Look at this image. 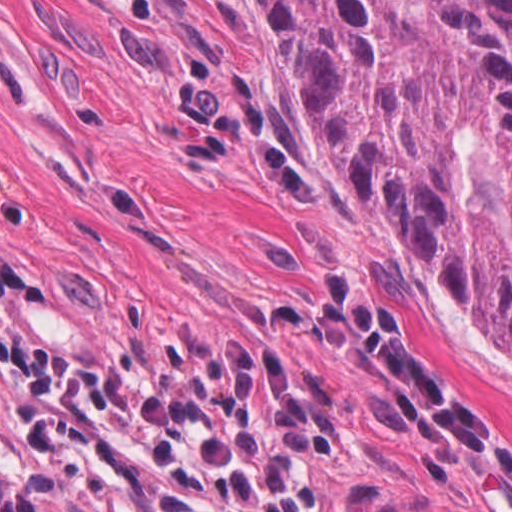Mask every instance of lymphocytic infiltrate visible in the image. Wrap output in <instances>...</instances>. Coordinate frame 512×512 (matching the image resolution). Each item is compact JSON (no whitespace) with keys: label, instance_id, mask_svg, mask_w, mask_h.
Masks as SVG:
<instances>
[{"label":"lymphocytic infiltrate","instance_id":"f902f5d3","mask_svg":"<svg viewBox=\"0 0 512 512\" xmlns=\"http://www.w3.org/2000/svg\"><path fill=\"white\" fill-rule=\"evenodd\" d=\"M37 289L0 252V391L37 470L93 512H334V407L298 360L337 351L390 378L425 432L512 481V432L408 350L366 289L283 307L267 347L153 350L95 368L36 350L15 317Z\"/></svg>","mask_w":512,"mask_h":512}]
</instances>
